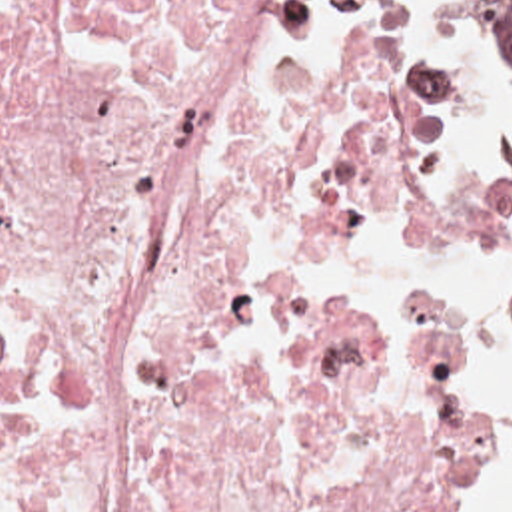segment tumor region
Segmentation results:
<instances>
[{
    "label": "tumor region",
    "mask_w": 512,
    "mask_h": 512,
    "mask_svg": "<svg viewBox=\"0 0 512 512\" xmlns=\"http://www.w3.org/2000/svg\"><path fill=\"white\" fill-rule=\"evenodd\" d=\"M471 5L493 49L512 59V0H471ZM503 346L512 348V319L501 348Z\"/></svg>",
    "instance_id": "e687c5a6"
}]
</instances>
